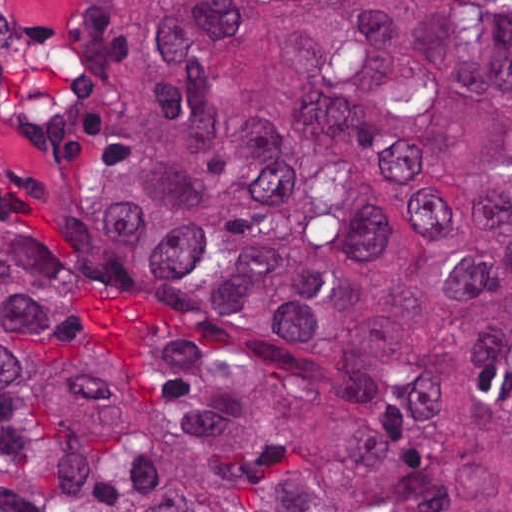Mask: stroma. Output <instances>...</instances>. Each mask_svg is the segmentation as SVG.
I'll list each match as a JSON object with an SVG mask.
<instances>
[{
  "label": "stroma",
  "instance_id": "obj_1",
  "mask_svg": "<svg viewBox=\"0 0 512 512\" xmlns=\"http://www.w3.org/2000/svg\"><path fill=\"white\" fill-rule=\"evenodd\" d=\"M141 101L128 15L117 0H0V164L28 202L0 206L86 272L123 352L158 365L178 331L141 288L102 276L95 237L112 157Z\"/></svg>",
  "mask_w": 512,
  "mask_h": 512
}]
</instances>
